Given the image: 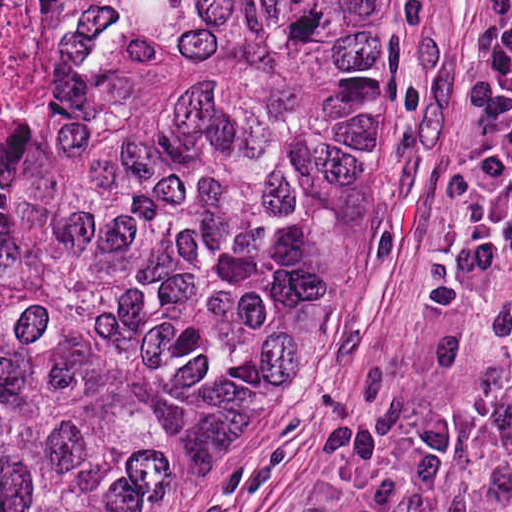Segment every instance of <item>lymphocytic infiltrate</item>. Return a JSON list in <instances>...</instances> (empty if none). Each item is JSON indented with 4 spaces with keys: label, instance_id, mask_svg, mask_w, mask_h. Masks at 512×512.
Returning a JSON list of instances; mask_svg holds the SVG:
<instances>
[{
    "label": "lymphocytic infiltrate",
    "instance_id": "1",
    "mask_svg": "<svg viewBox=\"0 0 512 512\" xmlns=\"http://www.w3.org/2000/svg\"><path fill=\"white\" fill-rule=\"evenodd\" d=\"M469 458L470 437L461 421L419 420L396 438L383 481L369 499L319 512H439Z\"/></svg>",
    "mask_w": 512,
    "mask_h": 512
}]
</instances>
